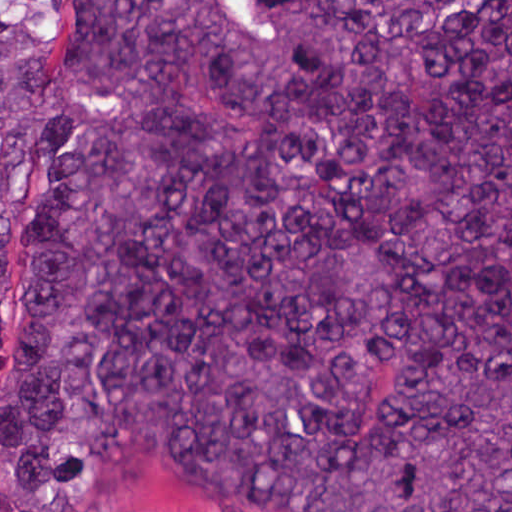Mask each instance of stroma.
Instances as JSON below:
<instances>
[{"instance_id": "obj_1", "label": "stroma", "mask_w": 512, "mask_h": 512, "mask_svg": "<svg viewBox=\"0 0 512 512\" xmlns=\"http://www.w3.org/2000/svg\"><path fill=\"white\" fill-rule=\"evenodd\" d=\"M65 1H512V0H0V15L23 17L44 41L60 28ZM4 384L0 362V390ZM88 512H261L209 491L156 441L135 445L105 469Z\"/></svg>"}]
</instances>
